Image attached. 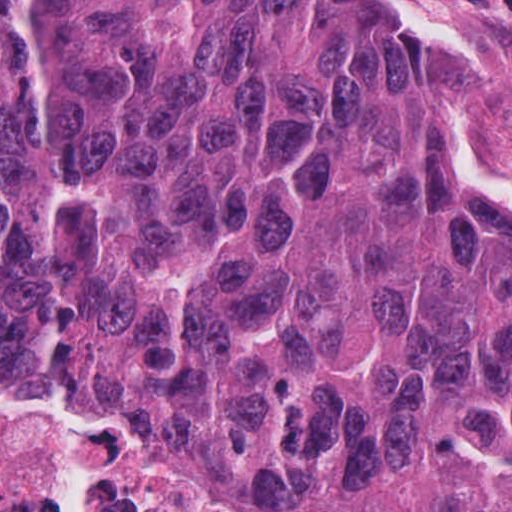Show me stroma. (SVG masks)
<instances>
[{"label":"stroma","instance_id":"obj_1","mask_svg":"<svg viewBox=\"0 0 512 512\" xmlns=\"http://www.w3.org/2000/svg\"><path fill=\"white\" fill-rule=\"evenodd\" d=\"M379 1L397 19L417 85L475 120L486 156L512 182V0Z\"/></svg>","mask_w":512,"mask_h":512}]
</instances>
